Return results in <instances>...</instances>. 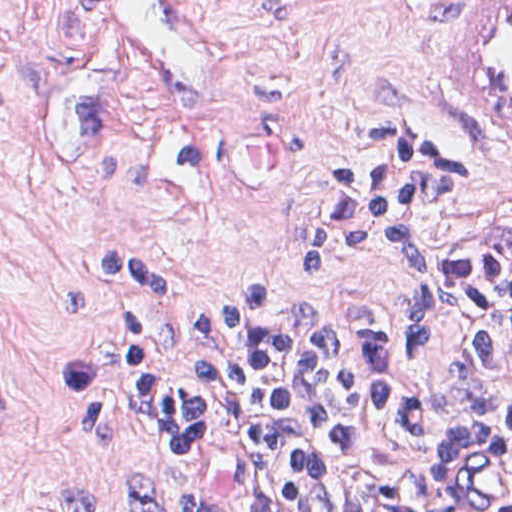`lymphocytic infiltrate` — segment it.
<instances>
[{
    "label": "lymphocytic infiltrate",
    "instance_id": "obj_1",
    "mask_svg": "<svg viewBox=\"0 0 512 512\" xmlns=\"http://www.w3.org/2000/svg\"><path fill=\"white\" fill-rule=\"evenodd\" d=\"M481 143V141H479ZM442 142L407 144L316 203L308 277L381 258L406 292L402 331L451 330L441 381L392 347L377 317L270 315L250 273L202 325L147 358V398L242 463L272 512H512V226L501 215L431 252L422 217L462 193ZM123 512H227L197 486L116 469ZM62 512H98L68 490Z\"/></svg>",
    "mask_w": 512,
    "mask_h": 512
}]
</instances>
